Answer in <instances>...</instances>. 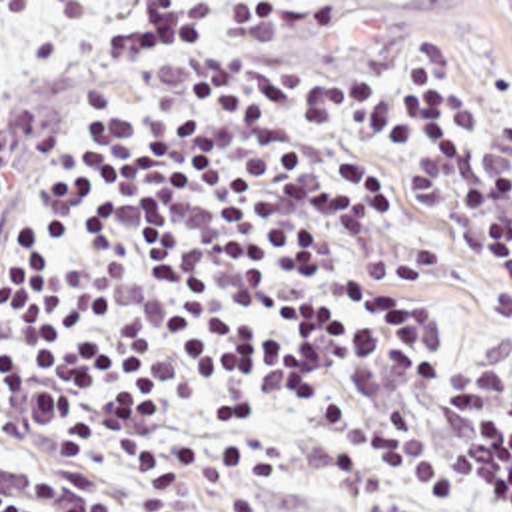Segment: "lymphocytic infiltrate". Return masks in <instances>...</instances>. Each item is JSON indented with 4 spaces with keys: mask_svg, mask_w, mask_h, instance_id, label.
Here are the masks:
<instances>
[{
    "mask_svg": "<svg viewBox=\"0 0 512 512\" xmlns=\"http://www.w3.org/2000/svg\"><path fill=\"white\" fill-rule=\"evenodd\" d=\"M512 512V84L24 136L0 168V512Z\"/></svg>",
    "mask_w": 512,
    "mask_h": 512,
    "instance_id": "1",
    "label": "lymphocytic infiltrate"
}]
</instances>
